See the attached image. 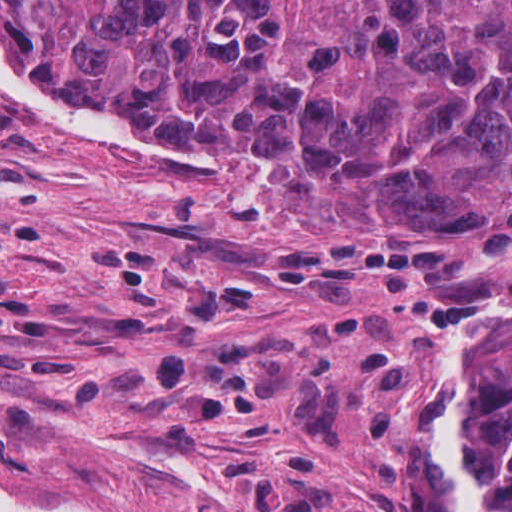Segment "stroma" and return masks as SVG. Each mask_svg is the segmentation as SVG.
<instances>
[{
    "mask_svg": "<svg viewBox=\"0 0 512 512\" xmlns=\"http://www.w3.org/2000/svg\"><path fill=\"white\" fill-rule=\"evenodd\" d=\"M137 116L211 154L79 134L0 88V477L115 512H460L452 335L512 303V237L362 241ZM511 342L512 314L477 512Z\"/></svg>",
    "mask_w": 512,
    "mask_h": 512,
    "instance_id": "1",
    "label": "stroma"
}]
</instances>
